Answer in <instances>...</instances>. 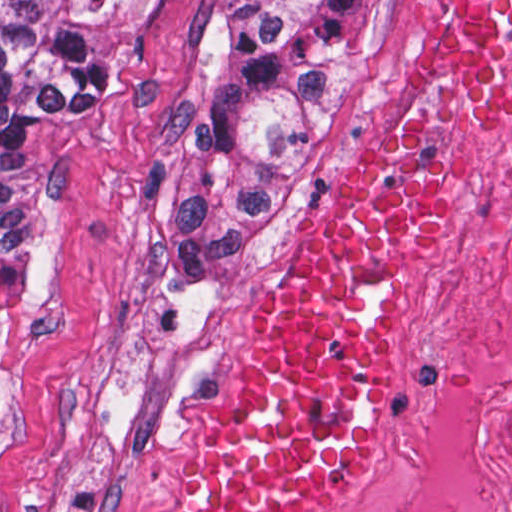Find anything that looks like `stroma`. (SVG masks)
<instances>
[{
	"instance_id": "obj_1",
	"label": "stroma",
	"mask_w": 512,
	"mask_h": 512,
	"mask_svg": "<svg viewBox=\"0 0 512 512\" xmlns=\"http://www.w3.org/2000/svg\"><path fill=\"white\" fill-rule=\"evenodd\" d=\"M218 3L141 0L117 83L83 107L37 113L10 138L38 279L0 420V512L186 505L208 443L246 398L264 322L407 93L435 0L389 1L328 170L272 230L172 258L152 242V215L208 72ZM499 127L423 108V161L437 175L441 213L429 250L383 307L367 448L344 487L309 512H341L417 436L445 374L476 166Z\"/></svg>"
}]
</instances>
